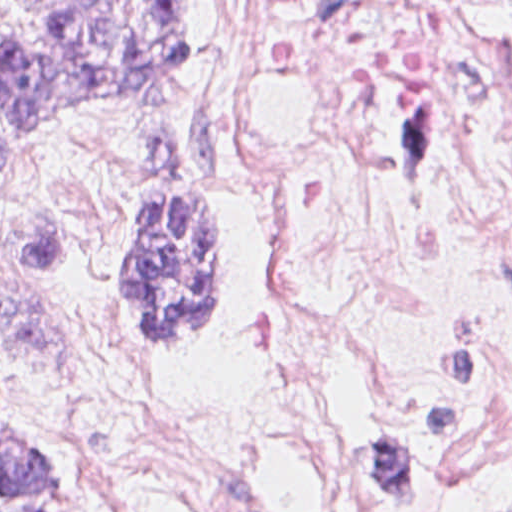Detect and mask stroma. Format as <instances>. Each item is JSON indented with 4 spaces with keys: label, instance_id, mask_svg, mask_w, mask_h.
<instances>
[{
    "label": "stroma",
    "instance_id": "stroma-1",
    "mask_svg": "<svg viewBox=\"0 0 512 512\" xmlns=\"http://www.w3.org/2000/svg\"><path fill=\"white\" fill-rule=\"evenodd\" d=\"M512 54L503 0H452ZM219 0H196L194 71L127 109L41 128L24 183L0 182V403L61 455L90 512H147L109 467L89 390L109 342L148 346L122 311L118 236L138 198L192 191L231 203L234 240L220 292L224 337L242 318L257 266L243 117L227 86ZM206 340V339H203ZM378 512L324 477L256 487L211 512Z\"/></svg>",
    "mask_w": 512,
    "mask_h": 512
}]
</instances>
